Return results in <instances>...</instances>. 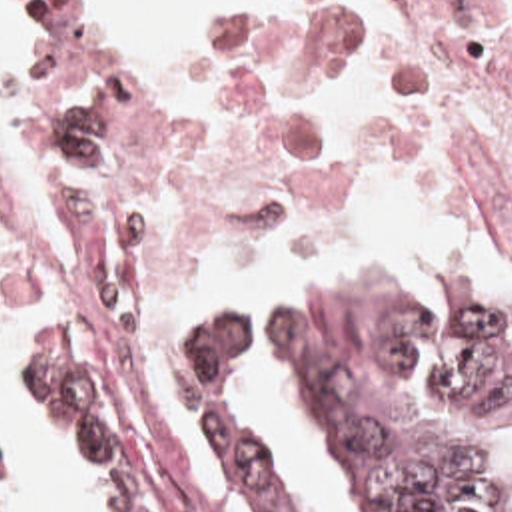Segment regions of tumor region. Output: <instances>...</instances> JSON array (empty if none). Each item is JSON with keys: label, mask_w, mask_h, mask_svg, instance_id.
<instances>
[{"label": "tumor region", "mask_w": 512, "mask_h": 512, "mask_svg": "<svg viewBox=\"0 0 512 512\" xmlns=\"http://www.w3.org/2000/svg\"><path fill=\"white\" fill-rule=\"evenodd\" d=\"M78 330L74 318H28L14 387L98 475L102 512H152ZM268 346L286 356L366 512H512V310L502 302L410 278H310L276 292ZM244 354V324L230 314L178 336L170 395L200 459L206 419L220 407L254 467L262 512H310L224 381Z\"/></svg>", "instance_id": "e687c5a6"}]
</instances>
